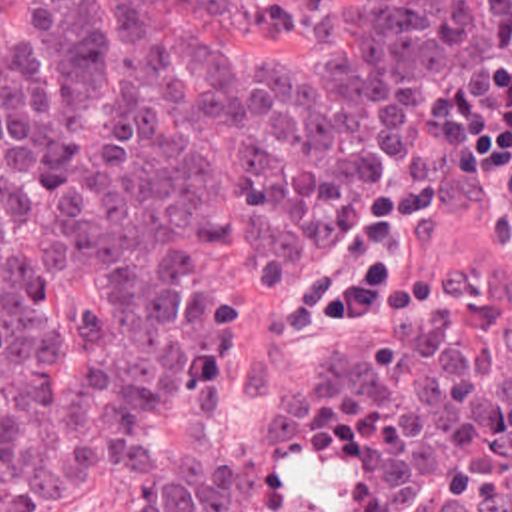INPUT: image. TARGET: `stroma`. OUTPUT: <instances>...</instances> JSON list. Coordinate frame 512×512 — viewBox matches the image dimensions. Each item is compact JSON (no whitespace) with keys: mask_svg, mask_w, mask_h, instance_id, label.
<instances>
[{"mask_svg":"<svg viewBox=\"0 0 512 512\" xmlns=\"http://www.w3.org/2000/svg\"><path fill=\"white\" fill-rule=\"evenodd\" d=\"M158 17L214 53L316 57L338 43L330 31L316 39H296L284 45H250L174 5H160ZM27 25L29 0H0V37L11 39ZM206 271L224 281L232 297L226 329V373L216 391L154 423L150 441L164 459L188 477L216 479L238 465V512H264L272 477V413L290 389L310 375V345L302 333L280 341L264 389L254 391L250 363L266 319V291L236 245L224 237L210 241ZM138 505L140 487L136 481L102 475L54 512H134Z\"/></svg>","mask_w":512,"mask_h":512,"instance_id":"obj_1","label":"stroma"}]
</instances>
